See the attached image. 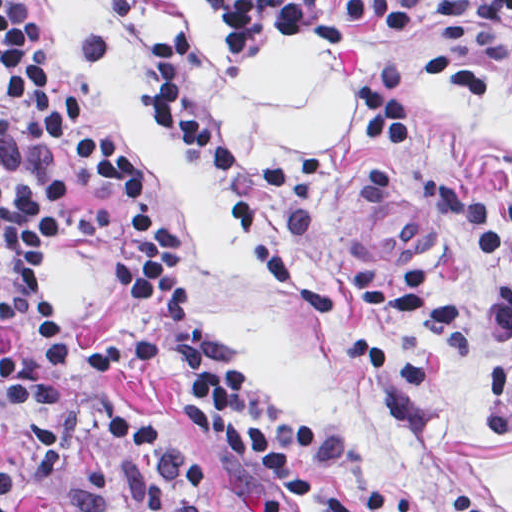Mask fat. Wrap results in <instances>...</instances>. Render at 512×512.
I'll return each instance as SVG.
<instances>
[{"instance_id": "fat-1", "label": "fat", "mask_w": 512, "mask_h": 512, "mask_svg": "<svg viewBox=\"0 0 512 512\" xmlns=\"http://www.w3.org/2000/svg\"><path fill=\"white\" fill-rule=\"evenodd\" d=\"M175 2L183 19L203 27L202 46L220 65L230 51L224 23L203 0ZM357 86V74L317 42L276 34L217 90V112L234 151L296 162L349 133Z\"/></svg>"}]
</instances>
